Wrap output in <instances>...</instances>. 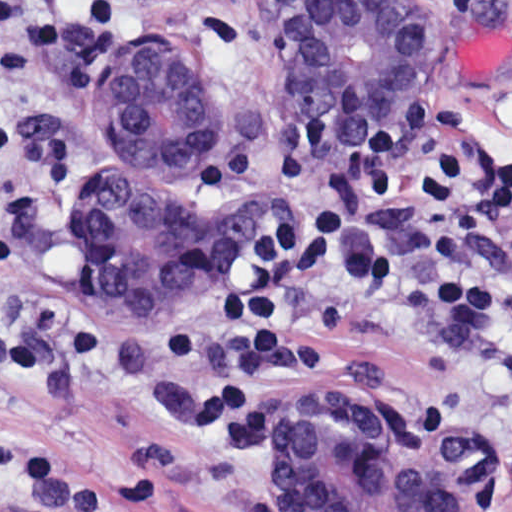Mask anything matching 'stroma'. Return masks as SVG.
Returning <instances> with one entry per match:
<instances>
[{
	"label": "stroma",
	"mask_w": 512,
	"mask_h": 512,
	"mask_svg": "<svg viewBox=\"0 0 512 512\" xmlns=\"http://www.w3.org/2000/svg\"><path fill=\"white\" fill-rule=\"evenodd\" d=\"M297 1L0 0V130L18 134L20 148L50 149L70 171L68 198L29 235L20 267L0 272V329L49 303L73 308L86 327V351L65 386L47 395L0 393V438L66 452L91 476L134 468L156 496L150 512L287 510L275 488V443L266 451H226L199 419V396L164 371V348L217 314L225 269L201 275L178 320L132 321L71 234L67 212L85 170L91 102L126 48L145 35V18L164 9L219 18L227 37V117L198 171L202 187L208 197L279 209L280 193L256 179L211 194L203 164L213 150L248 142H263L271 153L274 120L296 110L281 74V27ZM361 1H409L375 3L406 5L421 19V43L370 128L406 98L451 97L463 108L456 135L463 159L495 148L512 165V0ZM328 129L330 136L362 133ZM330 189L352 223L391 243L382 267H342L332 291L337 303L379 301L401 287L512 290V280L496 278L471 244L468 273L439 284L423 278L417 260L427 222L410 194L368 202L350 179ZM335 341L350 354L281 394V417L295 398L317 390H364L443 447L484 465L488 512H512L511 342L461 355L442 342ZM26 504L0 487V512Z\"/></svg>",
	"instance_id": "stroma-1"
}]
</instances>
